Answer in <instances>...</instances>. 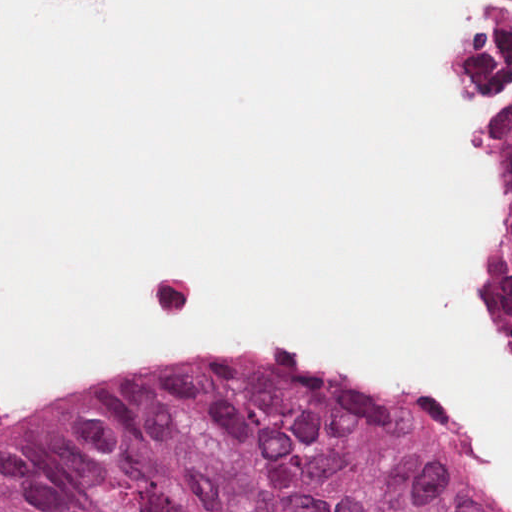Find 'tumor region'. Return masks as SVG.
Instances as JSON below:
<instances>
[{
	"label": "tumor region",
	"instance_id": "e687c5a6",
	"mask_svg": "<svg viewBox=\"0 0 512 512\" xmlns=\"http://www.w3.org/2000/svg\"><path fill=\"white\" fill-rule=\"evenodd\" d=\"M473 80L498 238L477 303L512 363V1H480ZM0 512H499L407 420L285 361H175L0 443Z\"/></svg>",
	"mask_w": 512,
	"mask_h": 512
}]
</instances>
